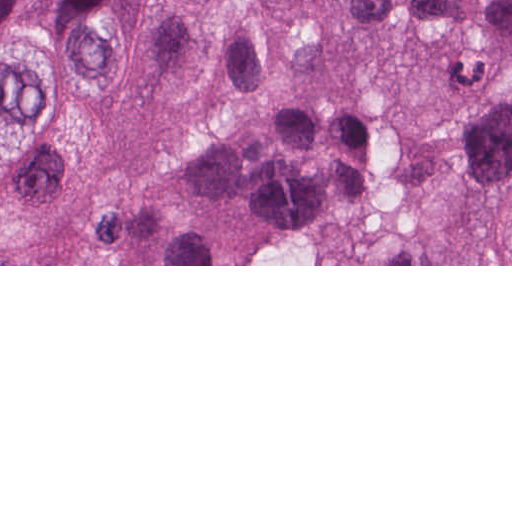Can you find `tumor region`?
I'll return each mask as SVG.
<instances>
[{
	"instance_id": "obj_1",
	"label": "tumor region",
	"mask_w": 512,
	"mask_h": 512,
	"mask_svg": "<svg viewBox=\"0 0 512 512\" xmlns=\"http://www.w3.org/2000/svg\"><path fill=\"white\" fill-rule=\"evenodd\" d=\"M0 265H512V0H0Z\"/></svg>"
}]
</instances>
